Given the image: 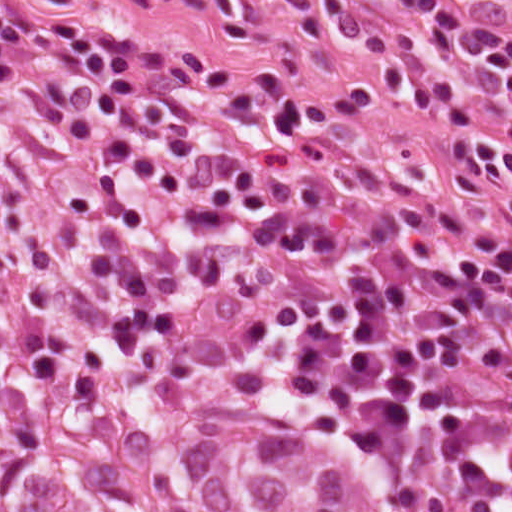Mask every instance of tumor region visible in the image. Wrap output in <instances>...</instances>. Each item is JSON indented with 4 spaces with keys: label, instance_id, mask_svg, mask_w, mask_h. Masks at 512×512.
<instances>
[{
    "label": "tumor region",
    "instance_id": "1",
    "mask_svg": "<svg viewBox=\"0 0 512 512\" xmlns=\"http://www.w3.org/2000/svg\"><path fill=\"white\" fill-rule=\"evenodd\" d=\"M64 298L89 327L0 332V512H454L400 457Z\"/></svg>",
    "mask_w": 512,
    "mask_h": 512
}]
</instances>
